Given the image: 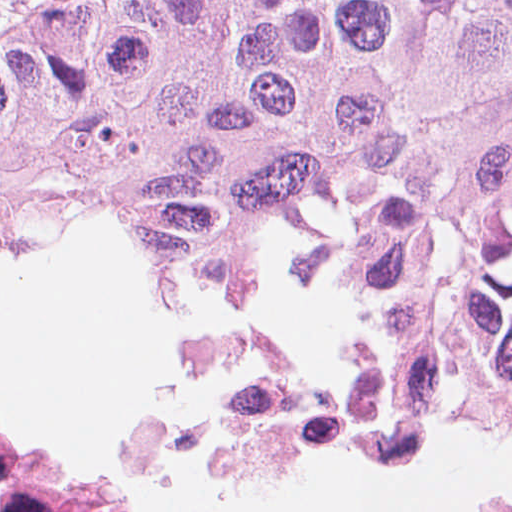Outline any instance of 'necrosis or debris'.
I'll return each instance as SVG.
<instances>
[{
	"instance_id": "necrosis-or-debris-1",
	"label": "necrosis or debris",
	"mask_w": 512,
	"mask_h": 512,
	"mask_svg": "<svg viewBox=\"0 0 512 512\" xmlns=\"http://www.w3.org/2000/svg\"><path fill=\"white\" fill-rule=\"evenodd\" d=\"M197 383L219 405L208 453L215 473L230 480L313 446L366 447L384 464L419 462L454 420L512 432V378L453 350L391 343ZM0 512L136 510L62 476L0 431Z\"/></svg>"
}]
</instances>
